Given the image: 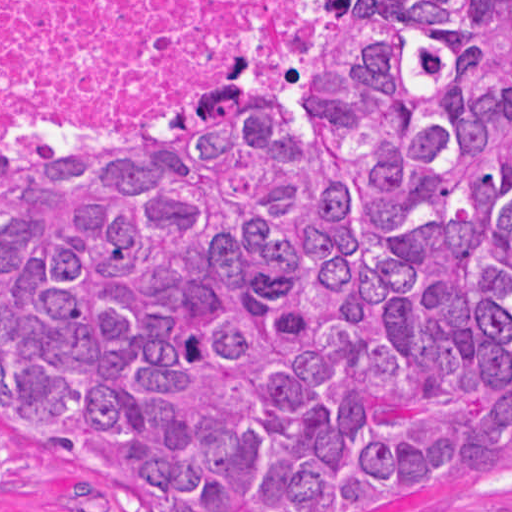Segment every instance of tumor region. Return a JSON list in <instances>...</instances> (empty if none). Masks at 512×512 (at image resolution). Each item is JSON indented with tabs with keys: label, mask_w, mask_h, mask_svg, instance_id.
Wrapping results in <instances>:
<instances>
[{
	"label": "tumor region",
	"mask_w": 512,
	"mask_h": 512,
	"mask_svg": "<svg viewBox=\"0 0 512 512\" xmlns=\"http://www.w3.org/2000/svg\"><path fill=\"white\" fill-rule=\"evenodd\" d=\"M0 424L162 512H419L512 437V0H373L259 109L0 173Z\"/></svg>",
	"instance_id": "tumor-region-1"
}]
</instances>
